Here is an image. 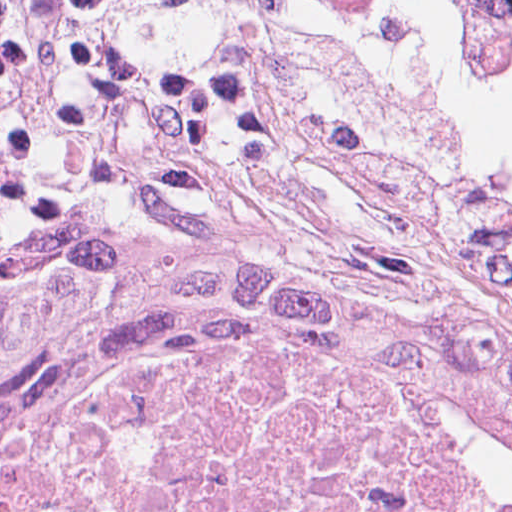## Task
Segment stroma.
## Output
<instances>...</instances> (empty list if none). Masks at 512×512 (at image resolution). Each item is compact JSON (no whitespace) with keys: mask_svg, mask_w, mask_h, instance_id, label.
Wrapping results in <instances>:
<instances>
[{"mask_svg":"<svg viewBox=\"0 0 512 512\" xmlns=\"http://www.w3.org/2000/svg\"><path fill=\"white\" fill-rule=\"evenodd\" d=\"M186 9L0 0V264L237 227H420L512 319V220L464 153L299 46L177 45Z\"/></svg>","mask_w":512,"mask_h":512,"instance_id":"stroma-1","label":"stroma"}]
</instances>
